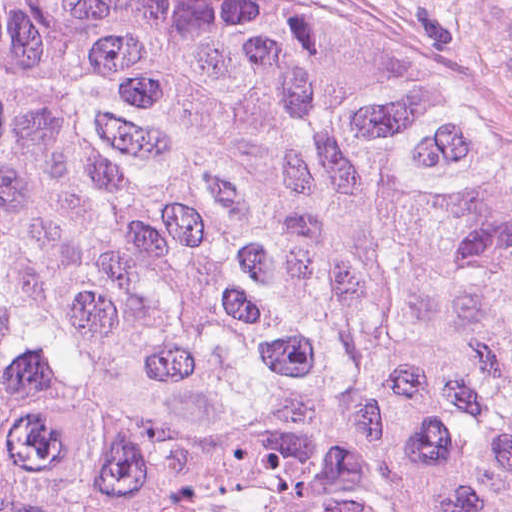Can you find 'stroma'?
Here are the masks:
<instances>
[{
	"label": "stroma",
	"instance_id": "35a3bbf8",
	"mask_svg": "<svg viewBox=\"0 0 512 512\" xmlns=\"http://www.w3.org/2000/svg\"><path fill=\"white\" fill-rule=\"evenodd\" d=\"M269 29L359 39L512 143V0H181Z\"/></svg>",
	"mask_w": 512,
	"mask_h": 512
}]
</instances>
